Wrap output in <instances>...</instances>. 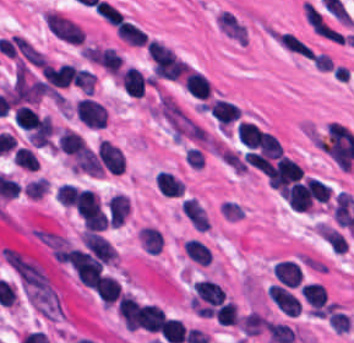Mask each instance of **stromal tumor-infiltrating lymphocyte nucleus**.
<instances>
[{
	"instance_id": "stromal-tumor-infiltrating-lymphocyte-nucleus-1",
	"label": "stromal tumor-infiltrating lymphocyte nucleus",
	"mask_w": 354,
	"mask_h": 343,
	"mask_svg": "<svg viewBox=\"0 0 354 343\" xmlns=\"http://www.w3.org/2000/svg\"><path fill=\"white\" fill-rule=\"evenodd\" d=\"M183 87L193 97L207 98L211 87L205 76L195 70H188Z\"/></svg>"
}]
</instances>
